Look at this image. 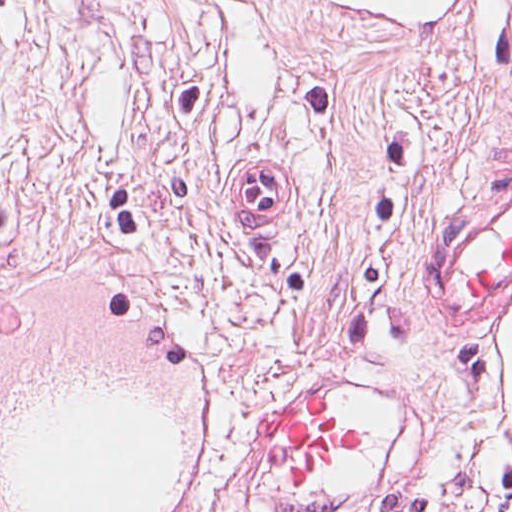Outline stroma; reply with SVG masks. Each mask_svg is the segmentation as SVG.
Masks as SVG:
<instances>
[{
    "instance_id": "1",
    "label": "stroma",
    "mask_w": 512,
    "mask_h": 512,
    "mask_svg": "<svg viewBox=\"0 0 512 512\" xmlns=\"http://www.w3.org/2000/svg\"><path fill=\"white\" fill-rule=\"evenodd\" d=\"M245 159L292 204L243 217ZM512 175V0L408 27L352 0H0V294L152 303L222 400L203 512H393L512 482L490 315L419 297L436 220ZM367 442L304 492L260 475L279 387ZM356 415H354V414Z\"/></svg>"
}]
</instances>
